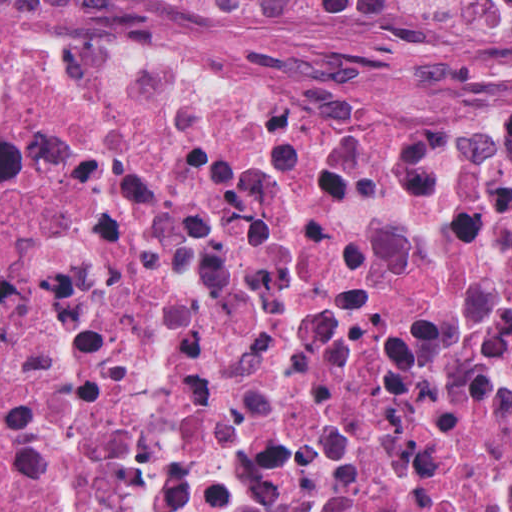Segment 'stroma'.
<instances>
[{
	"mask_svg": "<svg viewBox=\"0 0 512 512\" xmlns=\"http://www.w3.org/2000/svg\"><path fill=\"white\" fill-rule=\"evenodd\" d=\"M53 24L114 35L189 65L302 90H395L512 112V69H468L382 44H335L266 29L167 25L94 7H0V28Z\"/></svg>",
	"mask_w": 512,
	"mask_h": 512,
	"instance_id": "obj_1",
	"label": "stroma"
}]
</instances>
